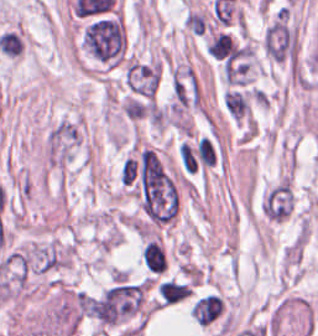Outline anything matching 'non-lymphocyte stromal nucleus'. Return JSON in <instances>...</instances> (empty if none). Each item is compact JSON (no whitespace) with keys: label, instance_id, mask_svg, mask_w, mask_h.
<instances>
[{"label":"non-lymphocyte stromal nucleus","instance_id":"non-lymphocyte-stromal-nucleus-1","mask_svg":"<svg viewBox=\"0 0 318 336\" xmlns=\"http://www.w3.org/2000/svg\"><path fill=\"white\" fill-rule=\"evenodd\" d=\"M83 141L80 118L65 115L56 120L42 141V163L45 169L66 177Z\"/></svg>","mask_w":318,"mask_h":336}]
</instances>
